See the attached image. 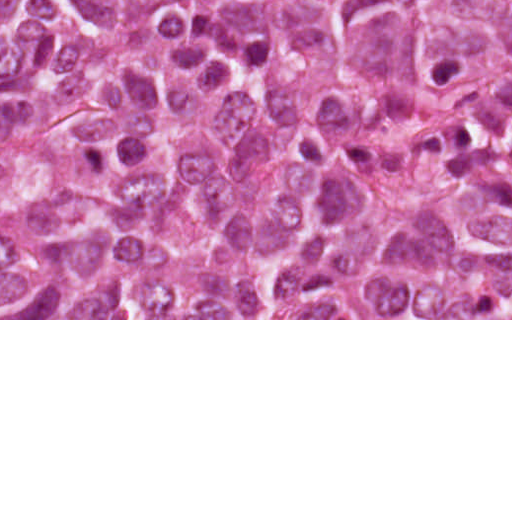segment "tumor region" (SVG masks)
<instances>
[{
	"label": "tumor region",
	"instance_id": "1",
	"mask_svg": "<svg viewBox=\"0 0 512 512\" xmlns=\"http://www.w3.org/2000/svg\"><path fill=\"white\" fill-rule=\"evenodd\" d=\"M1 318L512 319V0H1Z\"/></svg>",
	"mask_w": 512,
	"mask_h": 512
}]
</instances>
